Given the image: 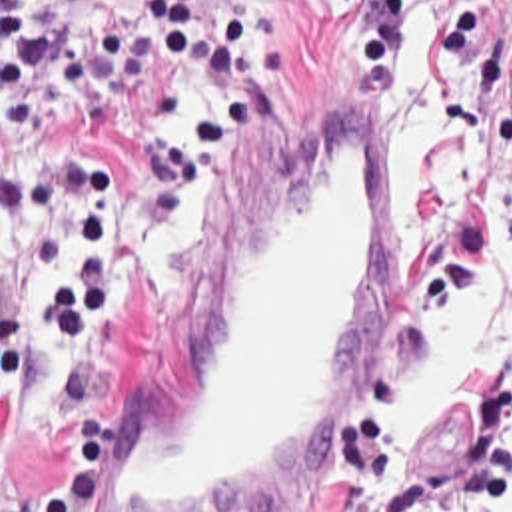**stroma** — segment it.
I'll list each match as a JSON object with an SVG mask.
<instances>
[{
  "label": "stroma",
  "instance_id": "35a3bbf8",
  "mask_svg": "<svg viewBox=\"0 0 512 512\" xmlns=\"http://www.w3.org/2000/svg\"><path fill=\"white\" fill-rule=\"evenodd\" d=\"M213 0H201L203 14ZM437 24V12L421 6ZM100 20L137 28L151 54V78L123 138L108 144L104 162L127 202L131 228V324L102 360L98 376L114 398V442L145 412L165 382L185 324L223 266L233 242L281 182L287 164L317 114L349 100L351 78L333 52V0H251V44L263 54V86L249 88L241 134L213 150L219 196L195 220V238L175 284H155L135 254L139 232V154L165 128L169 78L177 70L163 36L137 0H64V44ZM512 0H495L479 32L457 60H445V80L469 112L471 130L512 146ZM379 104V96L367 98ZM86 108L62 84V62L36 100L34 136L0 138V164L46 144L82 142ZM395 220V172L387 232ZM38 274V240L0 250V314L26 298ZM40 378L0 410V477L22 487L46 481L58 436L40 416ZM353 426V424H351ZM349 432L321 456L305 479L265 512H437L463 499L481 473V440L465 402L431 424L419 454L389 491L361 483L349 456ZM112 442V444H114Z\"/></svg>",
  "mask_w": 512,
  "mask_h": 512
}]
</instances>
